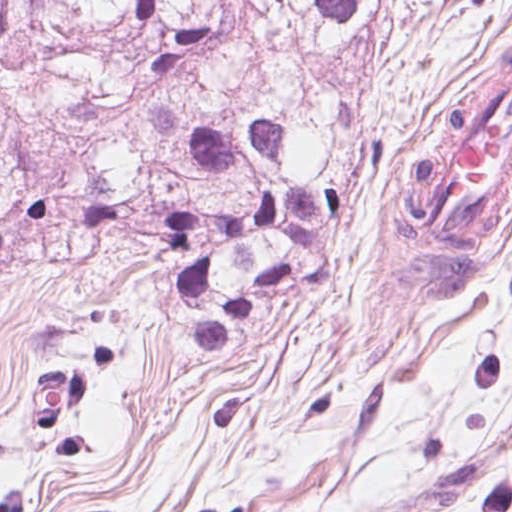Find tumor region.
Instances as JSON below:
<instances>
[{"label":"tumor region","instance_id":"e687c5a6","mask_svg":"<svg viewBox=\"0 0 512 512\" xmlns=\"http://www.w3.org/2000/svg\"><path fill=\"white\" fill-rule=\"evenodd\" d=\"M366 1L0 0V290L54 265L161 259L180 336L236 356L263 313L327 269L360 157L332 62ZM508 103L512 42L408 119L359 342H403L481 262L497 270L512 156L493 188L456 167L477 114Z\"/></svg>","mask_w":512,"mask_h":512}]
</instances>
